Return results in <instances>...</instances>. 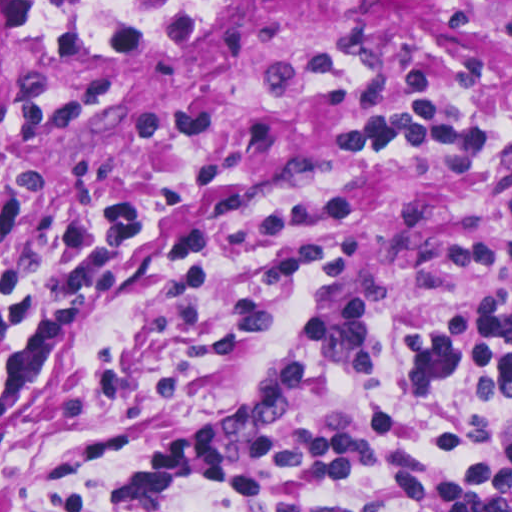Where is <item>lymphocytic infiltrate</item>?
<instances>
[{"label":"lymphocytic infiltrate","mask_w":512,"mask_h":512,"mask_svg":"<svg viewBox=\"0 0 512 512\" xmlns=\"http://www.w3.org/2000/svg\"><path fill=\"white\" fill-rule=\"evenodd\" d=\"M490 34H512V1H436ZM365 149L463 168H512V68L431 90L357 134ZM140 196H93L52 225L53 272L14 193L0 191V424L59 368L102 283L125 269ZM349 231L333 274L297 318L371 374L379 370L372 305L393 306L404 389L428 399L471 379L443 447L421 440L404 411L354 418L320 357L287 343L245 405L212 425L184 427L157 410L122 480L116 512H188L195 492L227 512H512V279L408 291L361 303L341 297ZM256 346V345H254ZM246 348L198 373L222 368Z\"/></svg>","instance_id":"obj_1"}]
</instances>
